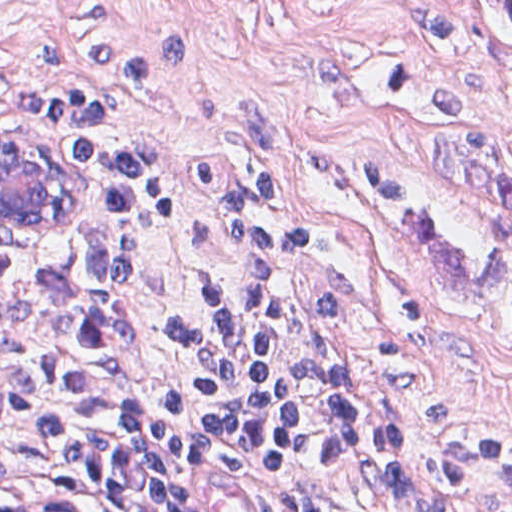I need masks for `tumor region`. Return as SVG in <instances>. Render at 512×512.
Instances as JSON below:
<instances>
[{"label":"tumor region","instance_id":"1","mask_svg":"<svg viewBox=\"0 0 512 512\" xmlns=\"http://www.w3.org/2000/svg\"><path fill=\"white\" fill-rule=\"evenodd\" d=\"M512 22V0H487ZM430 174L448 194L483 214L512 224V170L478 139L473 129L450 127L428 138Z\"/></svg>","mask_w":512,"mask_h":512}]
</instances>
